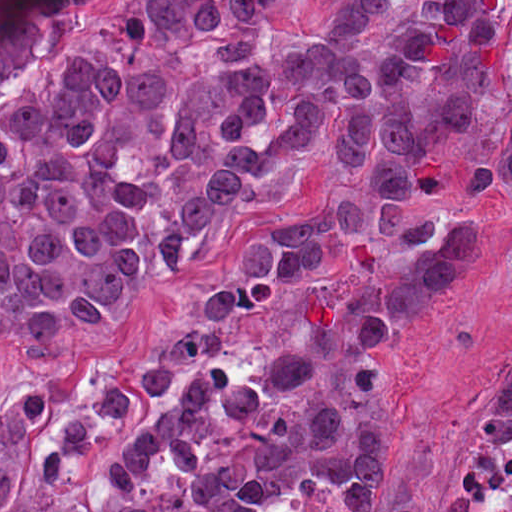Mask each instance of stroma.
Instances as JSON below:
<instances>
[{"label": "stroma", "mask_w": 512, "mask_h": 512, "mask_svg": "<svg viewBox=\"0 0 512 512\" xmlns=\"http://www.w3.org/2000/svg\"><path fill=\"white\" fill-rule=\"evenodd\" d=\"M476 389L402 421V435L396 426L384 467L385 500L416 512H457L455 488L467 450L512 422L481 412Z\"/></svg>", "instance_id": "stroma-1"}]
</instances>
